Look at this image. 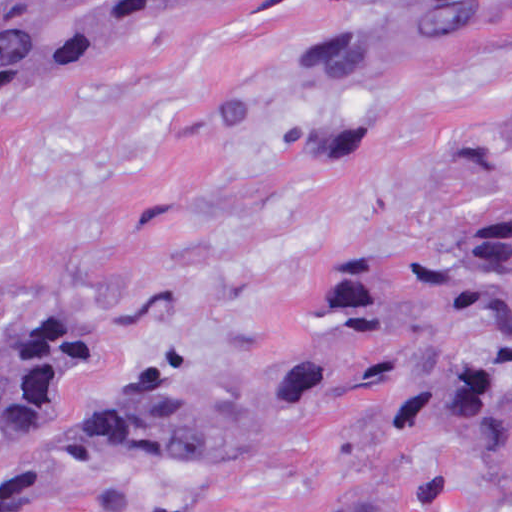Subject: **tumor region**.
<instances>
[{"label":"tumor region","instance_id":"tumor-region-1","mask_svg":"<svg viewBox=\"0 0 512 512\" xmlns=\"http://www.w3.org/2000/svg\"><path fill=\"white\" fill-rule=\"evenodd\" d=\"M227 0H0V116L35 81L117 40L174 27ZM512 17V0H386L320 37L290 87L343 97L336 125L304 145L312 165L366 153L365 89L378 78ZM512 161V106L496 131ZM325 332L267 377L372 389L445 432L502 489L512 512V193L444 252L347 260L322 290ZM105 348L73 316L45 313L0 340V461L36 447L46 412ZM203 393L189 366L132 380L111 424Z\"/></svg>","mask_w":512,"mask_h":512}]
</instances>
